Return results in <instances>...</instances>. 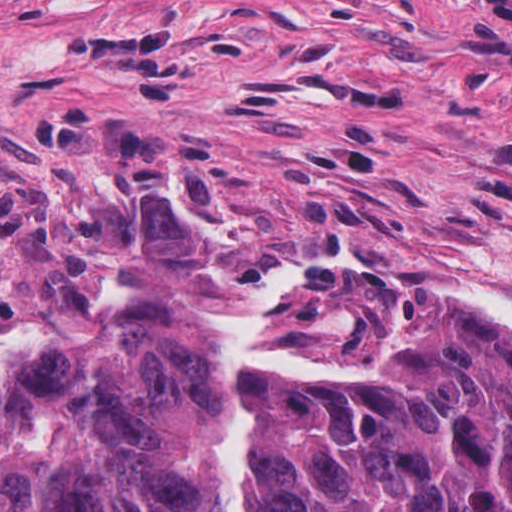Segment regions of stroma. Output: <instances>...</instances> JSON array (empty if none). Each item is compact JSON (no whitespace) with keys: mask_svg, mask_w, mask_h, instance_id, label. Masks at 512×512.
<instances>
[{"mask_svg":"<svg viewBox=\"0 0 512 512\" xmlns=\"http://www.w3.org/2000/svg\"><path fill=\"white\" fill-rule=\"evenodd\" d=\"M320 249L512 298V0H0V330Z\"/></svg>","mask_w":512,"mask_h":512,"instance_id":"1","label":"stroma"}]
</instances>
